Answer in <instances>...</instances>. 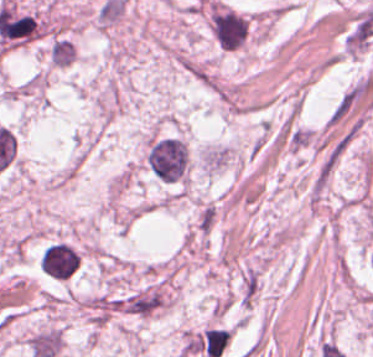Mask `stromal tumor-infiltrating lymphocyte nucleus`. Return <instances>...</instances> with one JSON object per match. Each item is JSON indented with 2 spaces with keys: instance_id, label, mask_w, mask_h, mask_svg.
I'll use <instances>...</instances> for the list:
<instances>
[{
  "instance_id": "stromal-tumor-infiltrating-lymphocyte-nucleus-1",
  "label": "stromal tumor-infiltrating lymphocyte nucleus",
  "mask_w": 373,
  "mask_h": 357,
  "mask_svg": "<svg viewBox=\"0 0 373 357\" xmlns=\"http://www.w3.org/2000/svg\"><path fill=\"white\" fill-rule=\"evenodd\" d=\"M49 57L54 66H68L76 58V47L68 39L55 37L50 45Z\"/></svg>"
}]
</instances>
